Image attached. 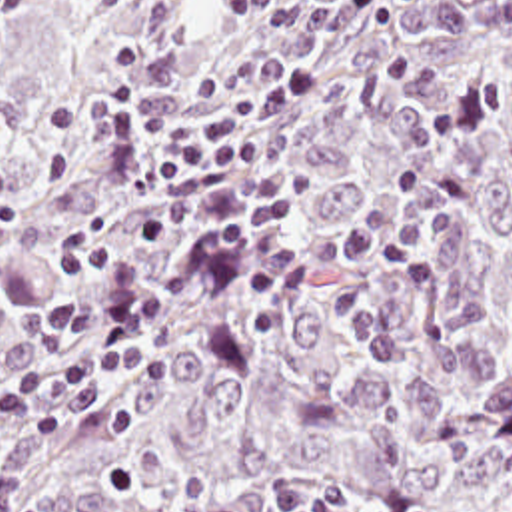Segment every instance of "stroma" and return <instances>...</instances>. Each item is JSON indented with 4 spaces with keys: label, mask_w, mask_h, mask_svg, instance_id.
<instances>
[{
    "label": "stroma",
    "mask_w": 512,
    "mask_h": 512,
    "mask_svg": "<svg viewBox=\"0 0 512 512\" xmlns=\"http://www.w3.org/2000/svg\"><path fill=\"white\" fill-rule=\"evenodd\" d=\"M45 0H0V44L7 40Z\"/></svg>",
    "instance_id": "obj_1"
}]
</instances>
